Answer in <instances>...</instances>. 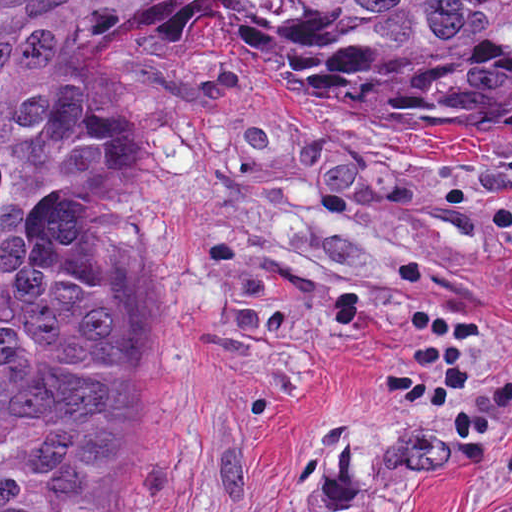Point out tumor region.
<instances>
[{"mask_svg": "<svg viewBox=\"0 0 512 512\" xmlns=\"http://www.w3.org/2000/svg\"><path fill=\"white\" fill-rule=\"evenodd\" d=\"M170 1L317 93L512 142V0H0V512H112L129 476L130 296L52 235L117 165L78 80Z\"/></svg>", "mask_w": 512, "mask_h": 512, "instance_id": "e687c5a6", "label": "tumor region"}]
</instances>
